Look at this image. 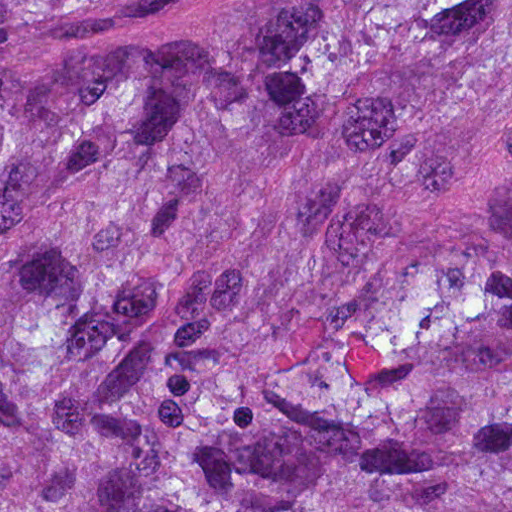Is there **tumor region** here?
I'll return each instance as SVG.
<instances>
[{
    "label": "tumor region",
    "mask_w": 512,
    "mask_h": 512,
    "mask_svg": "<svg viewBox=\"0 0 512 512\" xmlns=\"http://www.w3.org/2000/svg\"><path fill=\"white\" fill-rule=\"evenodd\" d=\"M0 512H512V0H0Z\"/></svg>",
    "instance_id": "e687c5a6"
}]
</instances>
